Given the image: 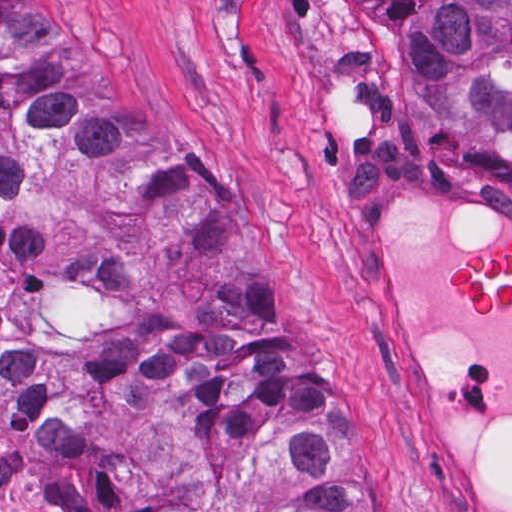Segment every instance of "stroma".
<instances>
[{
    "label": "stroma",
    "instance_id": "35a3bbf8",
    "mask_svg": "<svg viewBox=\"0 0 512 512\" xmlns=\"http://www.w3.org/2000/svg\"><path fill=\"white\" fill-rule=\"evenodd\" d=\"M28 2L131 118L204 170L381 440L404 512H439L380 390L356 192L374 162L412 155L512 204V127L470 136L435 122L370 0ZM0 512H42L1 412Z\"/></svg>",
    "mask_w": 512,
    "mask_h": 512
}]
</instances>
